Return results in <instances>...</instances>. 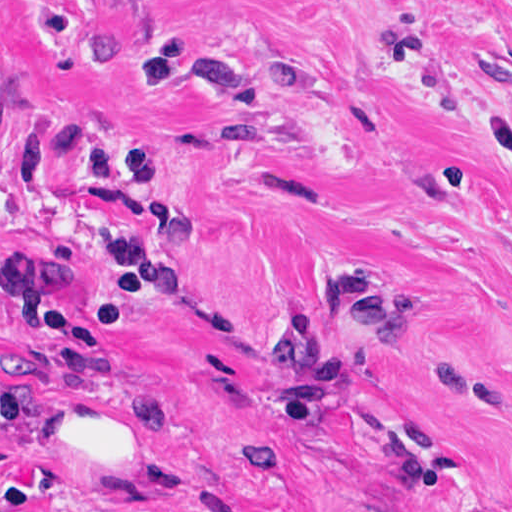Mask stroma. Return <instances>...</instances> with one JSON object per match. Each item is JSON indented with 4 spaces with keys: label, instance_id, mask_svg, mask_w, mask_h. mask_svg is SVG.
Returning a JSON list of instances; mask_svg holds the SVG:
<instances>
[{
    "label": "stroma",
    "instance_id": "1",
    "mask_svg": "<svg viewBox=\"0 0 512 512\" xmlns=\"http://www.w3.org/2000/svg\"><path fill=\"white\" fill-rule=\"evenodd\" d=\"M0 512H512V0H0Z\"/></svg>",
    "mask_w": 512,
    "mask_h": 512
}]
</instances>
